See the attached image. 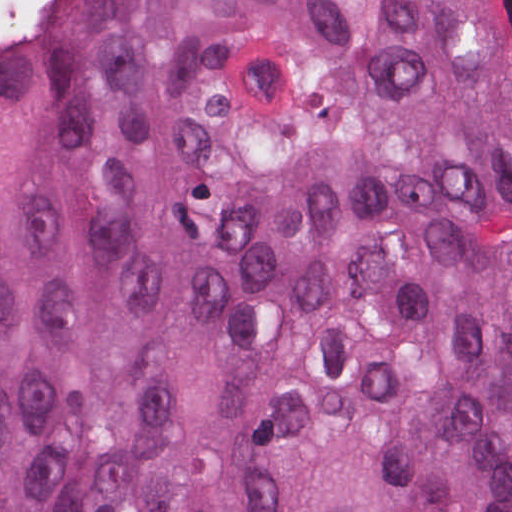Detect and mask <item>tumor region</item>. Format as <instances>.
<instances>
[{
	"mask_svg": "<svg viewBox=\"0 0 512 512\" xmlns=\"http://www.w3.org/2000/svg\"><path fill=\"white\" fill-rule=\"evenodd\" d=\"M0 512H512V1H43Z\"/></svg>",
	"mask_w": 512,
	"mask_h": 512,
	"instance_id": "1",
	"label": "tumor region"
}]
</instances>
